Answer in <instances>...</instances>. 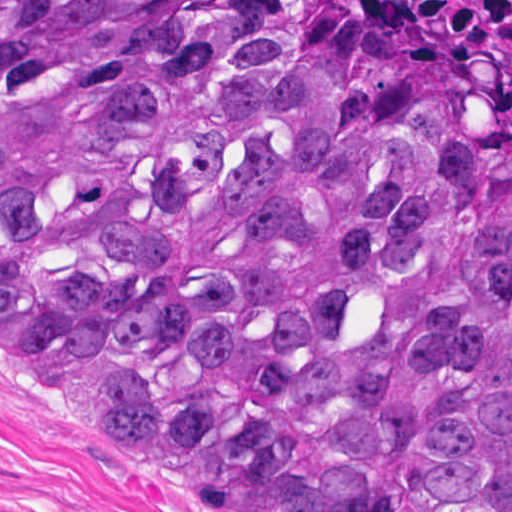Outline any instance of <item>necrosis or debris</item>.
<instances>
[{"label": "necrosis or debris", "mask_w": 512, "mask_h": 512, "mask_svg": "<svg viewBox=\"0 0 512 512\" xmlns=\"http://www.w3.org/2000/svg\"><path fill=\"white\" fill-rule=\"evenodd\" d=\"M480 71L512 106V0H379Z\"/></svg>", "instance_id": "obj_1"}]
</instances>
